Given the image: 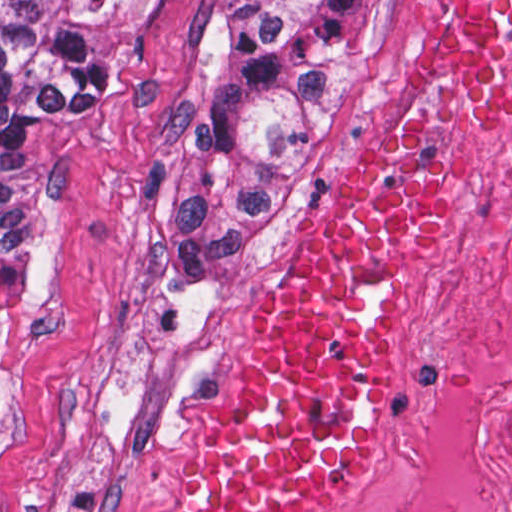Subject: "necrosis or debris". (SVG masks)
<instances>
[{
  "instance_id": "necrosis-or-debris-1",
  "label": "necrosis or debris",
  "mask_w": 512,
  "mask_h": 512,
  "mask_svg": "<svg viewBox=\"0 0 512 512\" xmlns=\"http://www.w3.org/2000/svg\"><path fill=\"white\" fill-rule=\"evenodd\" d=\"M341 512H512V122L476 166L444 378L417 436Z\"/></svg>"
}]
</instances>
